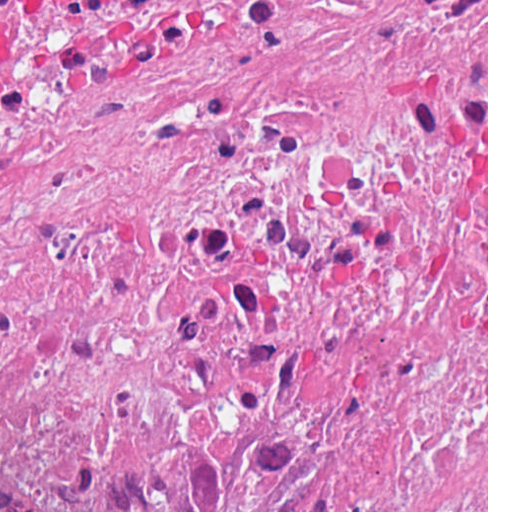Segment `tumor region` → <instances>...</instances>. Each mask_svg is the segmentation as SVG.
<instances>
[{
	"label": "tumor region",
	"mask_w": 512,
	"mask_h": 512,
	"mask_svg": "<svg viewBox=\"0 0 512 512\" xmlns=\"http://www.w3.org/2000/svg\"><path fill=\"white\" fill-rule=\"evenodd\" d=\"M63 512H487V414L394 429L274 490L123 497Z\"/></svg>",
	"instance_id": "e687c5a6"
}]
</instances>
